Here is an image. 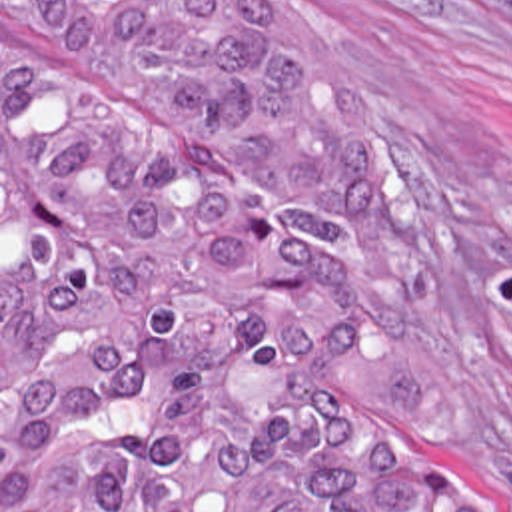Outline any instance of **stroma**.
Listing matches in <instances>:
<instances>
[{
	"label": "stroma",
	"mask_w": 512,
	"mask_h": 512,
	"mask_svg": "<svg viewBox=\"0 0 512 512\" xmlns=\"http://www.w3.org/2000/svg\"><path fill=\"white\" fill-rule=\"evenodd\" d=\"M268 1L309 27L347 79L399 189V227L375 235L337 225L367 283L357 363L483 512H512V0ZM8 37L20 59L156 121L202 163L309 209L268 161L224 147L194 117L126 99Z\"/></svg>",
	"instance_id": "35a3bbf8"
}]
</instances>
